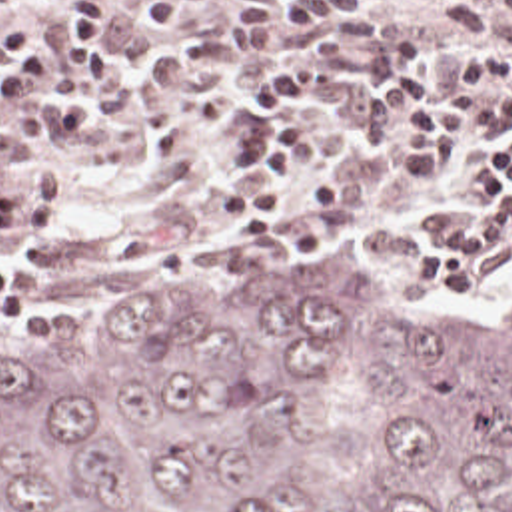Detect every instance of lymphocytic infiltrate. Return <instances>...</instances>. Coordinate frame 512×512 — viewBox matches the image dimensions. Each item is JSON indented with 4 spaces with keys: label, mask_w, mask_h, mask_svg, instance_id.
I'll return each instance as SVG.
<instances>
[{
    "label": "lymphocytic infiltrate",
    "mask_w": 512,
    "mask_h": 512,
    "mask_svg": "<svg viewBox=\"0 0 512 512\" xmlns=\"http://www.w3.org/2000/svg\"><path fill=\"white\" fill-rule=\"evenodd\" d=\"M17 0H0L1 9ZM199 15V0H65L49 25L71 61L53 77L43 43L11 25L0 39V109L17 101L45 129H77L89 103L115 81L107 51V29L147 21L171 41H185ZM317 61L261 59L245 81V123L231 139L229 156L239 170L259 172V182H241L217 196V226L233 246H265L277 240L293 216L337 212L347 206V170L329 168L307 192H299L305 170V133L291 123L295 99L311 91ZM409 99L415 115L397 148L409 174L441 180L453 166L459 142L485 141L477 158L465 160L473 184L481 186V208L453 230L417 246L413 282L437 292H469L487 260L512 236V45H483L457 63L453 81L419 65L409 67L361 101V129L385 135L399 103ZM0 316H21V278L0 262Z\"/></svg>",
    "instance_id": "obj_1"
}]
</instances>
